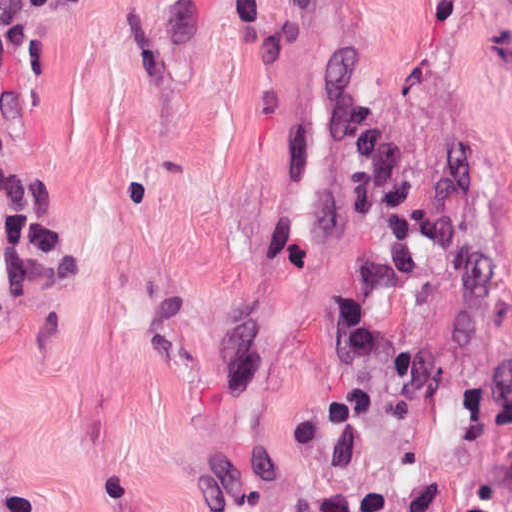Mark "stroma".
I'll return each mask as SVG.
<instances>
[{"label": "stroma", "mask_w": 512, "mask_h": 512, "mask_svg": "<svg viewBox=\"0 0 512 512\" xmlns=\"http://www.w3.org/2000/svg\"><path fill=\"white\" fill-rule=\"evenodd\" d=\"M0 166V512H512V0H90Z\"/></svg>", "instance_id": "35a3bbf8"}]
</instances>
